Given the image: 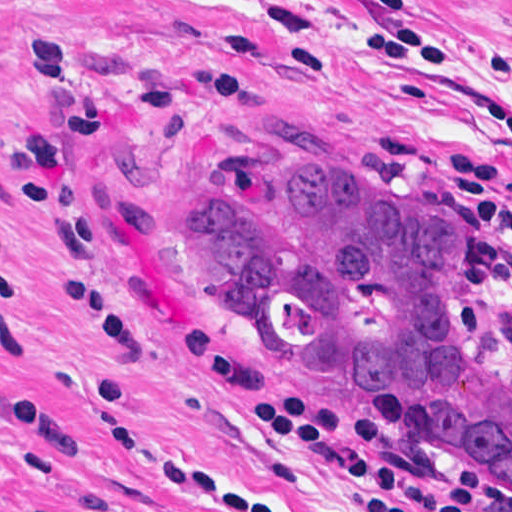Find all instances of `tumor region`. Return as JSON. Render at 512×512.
I'll use <instances>...</instances> for the list:
<instances>
[{
    "mask_svg": "<svg viewBox=\"0 0 512 512\" xmlns=\"http://www.w3.org/2000/svg\"><path fill=\"white\" fill-rule=\"evenodd\" d=\"M450 220L344 168H224L185 203L179 256L226 312L358 395L405 447L512 492V352L474 317Z\"/></svg>",
    "mask_w": 512,
    "mask_h": 512,
    "instance_id": "1",
    "label": "tumor region"
}]
</instances>
